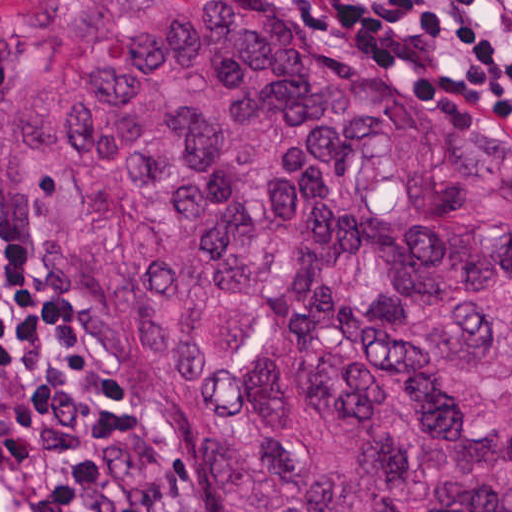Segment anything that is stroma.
Returning a JSON list of instances; mask_svg holds the SVG:
<instances>
[{
    "mask_svg": "<svg viewBox=\"0 0 512 512\" xmlns=\"http://www.w3.org/2000/svg\"><path fill=\"white\" fill-rule=\"evenodd\" d=\"M7 0H0V8ZM331 18L345 22L371 36L390 54L413 62L439 75L457 91L480 105L499 121L512 139V114L488 99L458 85L441 74L418 50L405 44L371 18L356 14L338 0H310ZM0 278L18 316L50 344L45 364L26 369L7 386H0V413L24 400L26 391L44 383H81L127 402L135 433L123 452V473L150 512H173L155 474L148 446L159 426L145 391L128 367L110 361L71 341L57 337L26 319L13 298V190L0 165Z\"/></svg>",
    "mask_w": 512,
    "mask_h": 512,
    "instance_id": "obj_1",
    "label": "stroma"
}]
</instances>
